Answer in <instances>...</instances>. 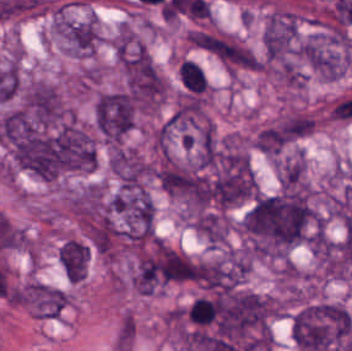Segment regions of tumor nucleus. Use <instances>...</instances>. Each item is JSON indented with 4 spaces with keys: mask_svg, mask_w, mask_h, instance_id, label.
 Here are the masks:
<instances>
[{
    "mask_svg": "<svg viewBox=\"0 0 352 351\" xmlns=\"http://www.w3.org/2000/svg\"><path fill=\"white\" fill-rule=\"evenodd\" d=\"M25 299L36 318H59L68 305L69 292L64 287L29 278Z\"/></svg>",
    "mask_w": 352,
    "mask_h": 351,
    "instance_id": "2f306a5c",
    "label": "tumor nucleus"
}]
</instances>
